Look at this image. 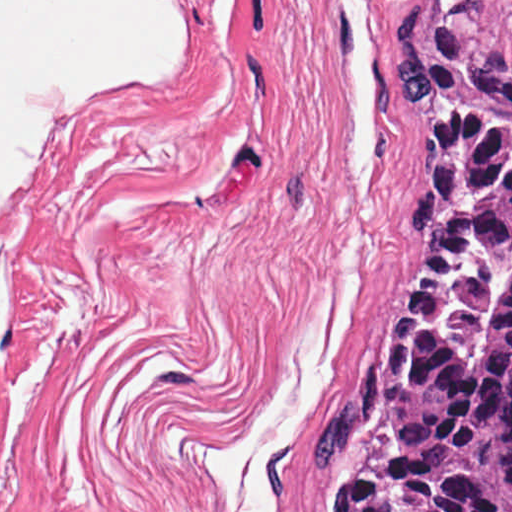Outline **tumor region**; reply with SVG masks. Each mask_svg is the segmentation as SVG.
I'll list each match as a JSON object with an SVG mask.
<instances>
[{"label":"tumor region","instance_id":"obj_1","mask_svg":"<svg viewBox=\"0 0 512 512\" xmlns=\"http://www.w3.org/2000/svg\"><path fill=\"white\" fill-rule=\"evenodd\" d=\"M421 251L311 461L318 512H512V33L392 21Z\"/></svg>","mask_w":512,"mask_h":512}]
</instances>
